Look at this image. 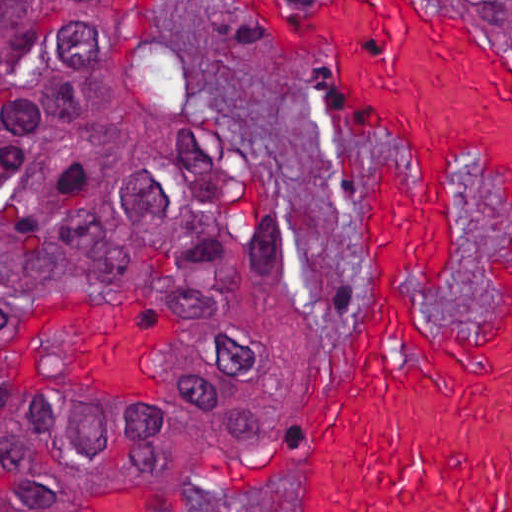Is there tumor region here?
<instances>
[{
	"label": "tumor region",
	"mask_w": 512,
	"mask_h": 512,
	"mask_svg": "<svg viewBox=\"0 0 512 512\" xmlns=\"http://www.w3.org/2000/svg\"><path fill=\"white\" fill-rule=\"evenodd\" d=\"M292 323L287 220L121 2L0 1V512L233 430Z\"/></svg>",
	"instance_id": "e687c5a6"
}]
</instances>
